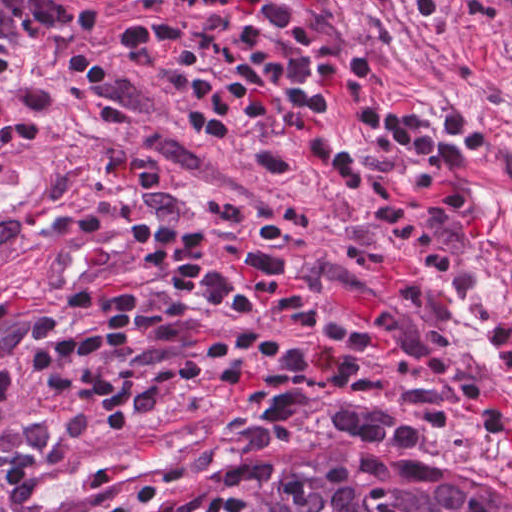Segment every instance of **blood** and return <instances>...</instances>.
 Instances as JSON below:
<instances>
[{
	"label": "blood",
	"instance_id": "blood-1",
	"mask_svg": "<svg viewBox=\"0 0 512 512\" xmlns=\"http://www.w3.org/2000/svg\"><path fill=\"white\" fill-rule=\"evenodd\" d=\"M243 279L259 277L256 268L249 266H235ZM338 293L337 303L354 319H377L382 316V297L377 295ZM331 361L334 359L324 340L322 339L311 359V370L315 375H326ZM485 407H504L511 409V393L504 388H493L485 393L478 401Z\"/></svg>",
	"mask_w": 512,
	"mask_h": 512
}]
</instances>
